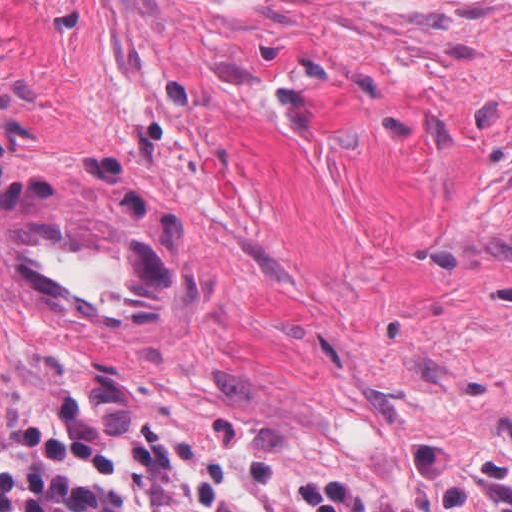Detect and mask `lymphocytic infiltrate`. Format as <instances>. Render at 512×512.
I'll return each instance as SVG.
<instances>
[{
	"label": "lymphocytic infiltrate",
	"instance_id": "obj_1",
	"mask_svg": "<svg viewBox=\"0 0 512 512\" xmlns=\"http://www.w3.org/2000/svg\"><path fill=\"white\" fill-rule=\"evenodd\" d=\"M0 512H309L284 464L250 431L163 426L127 452L53 416L0 426Z\"/></svg>",
	"mask_w": 512,
	"mask_h": 512
}]
</instances>
